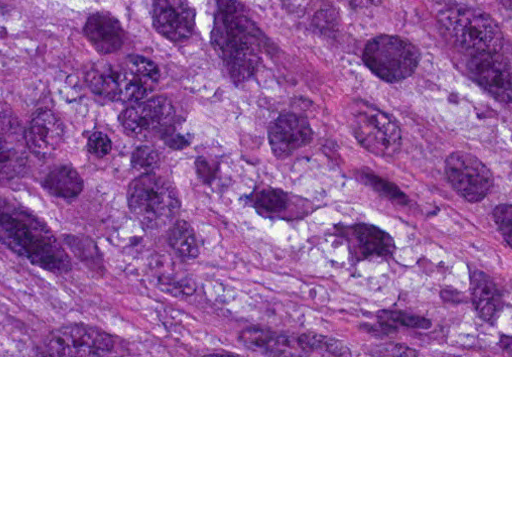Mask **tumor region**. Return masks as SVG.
I'll return each instance as SVG.
<instances>
[{"mask_svg":"<svg viewBox=\"0 0 512 512\" xmlns=\"http://www.w3.org/2000/svg\"><path fill=\"white\" fill-rule=\"evenodd\" d=\"M0 356H512V0H0Z\"/></svg>","mask_w":512,"mask_h":512,"instance_id":"tumor-region-1","label":"tumor region"}]
</instances>
